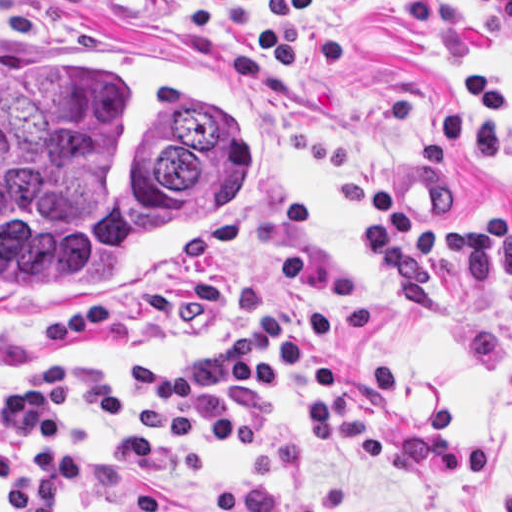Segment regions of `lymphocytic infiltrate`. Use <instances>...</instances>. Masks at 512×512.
Masks as SVG:
<instances>
[{
    "mask_svg": "<svg viewBox=\"0 0 512 512\" xmlns=\"http://www.w3.org/2000/svg\"><path fill=\"white\" fill-rule=\"evenodd\" d=\"M189 1L203 34L247 32L268 48L241 46L237 64L254 80L278 87H310L308 53L348 70V30L319 19L332 0ZM512 34V0H480ZM387 17L412 27L431 46L437 38L430 0H375ZM362 252L394 287L403 309L433 311L435 259L459 264L461 284L484 286L512 278V215H434L400 205L397 193L376 197ZM297 386L307 414V439L320 456L348 441L365 464L388 460L380 421L347 388L345 360L301 338L264 283L242 285L235 337L180 364L136 366L134 411L142 427L133 440H102L72 425L73 407H91L118 421L130 405L118 377L86 360L45 358L20 383L0 389V487L19 512H56L61 499L99 512H184L155 487L203 478V447L252 451L260 420L222 416L204 420L206 399L249 403ZM95 452L117 479L98 473L66 449ZM146 481L148 484L141 482ZM210 512H323L314 498L283 497L270 483L224 488Z\"/></svg>",
    "mask_w": 512,
    "mask_h": 512,
    "instance_id": "f902f5d3",
    "label": "lymphocytic infiltrate"
}]
</instances>
